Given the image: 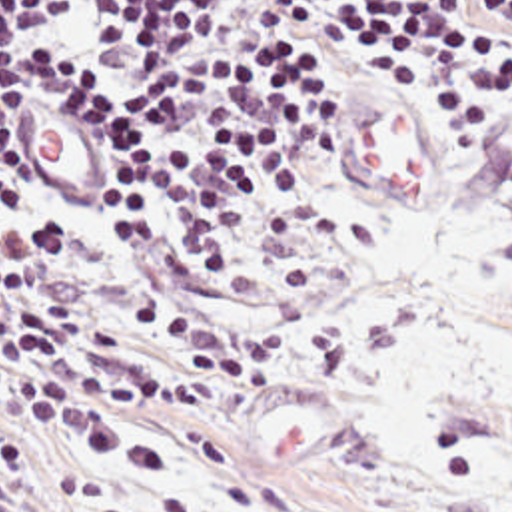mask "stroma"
I'll return each instance as SVG.
<instances>
[{
	"label": "stroma",
	"instance_id": "obj_1",
	"mask_svg": "<svg viewBox=\"0 0 512 512\" xmlns=\"http://www.w3.org/2000/svg\"><path fill=\"white\" fill-rule=\"evenodd\" d=\"M336 117L293 231L205 370L131 358L149 400L103 432L0 398V512H508L512 83L410 89L306 59ZM35 193L93 207L111 159L41 99L15 145Z\"/></svg>",
	"mask_w": 512,
	"mask_h": 512
}]
</instances>
